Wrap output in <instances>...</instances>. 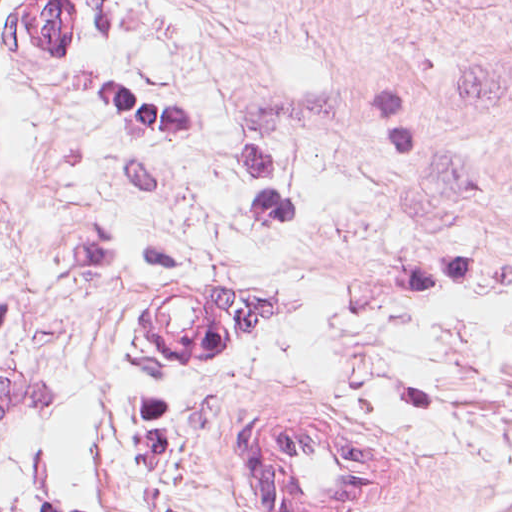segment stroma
Listing matches in <instances>:
<instances>
[{
  "label": "stroma",
  "mask_w": 512,
  "mask_h": 512,
  "mask_svg": "<svg viewBox=\"0 0 512 512\" xmlns=\"http://www.w3.org/2000/svg\"><path fill=\"white\" fill-rule=\"evenodd\" d=\"M0 0V512H263L234 415L512 512V0ZM252 304L205 368L124 324Z\"/></svg>",
  "instance_id": "obj_1"
}]
</instances>
